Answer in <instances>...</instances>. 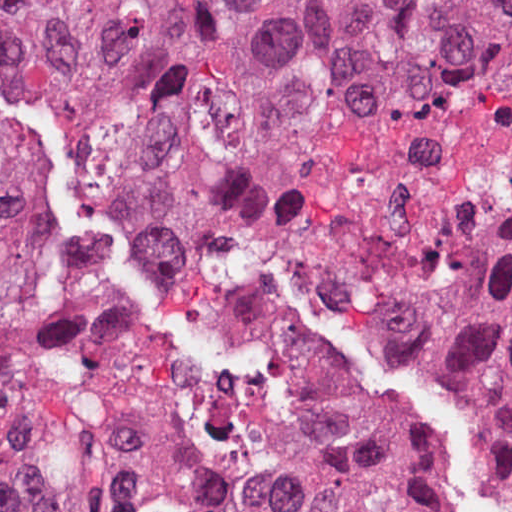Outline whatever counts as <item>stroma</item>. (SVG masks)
Segmentation results:
<instances>
[{
  "label": "stroma",
  "mask_w": 512,
  "mask_h": 512,
  "mask_svg": "<svg viewBox=\"0 0 512 512\" xmlns=\"http://www.w3.org/2000/svg\"><path fill=\"white\" fill-rule=\"evenodd\" d=\"M21 301L2 396L45 512H512V482L351 344L340 260L512 234V90L393 71L212 173L78 118L1 128Z\"/></svg>",
  "instance_id": "35a3bbf8"
}]
</instances>
